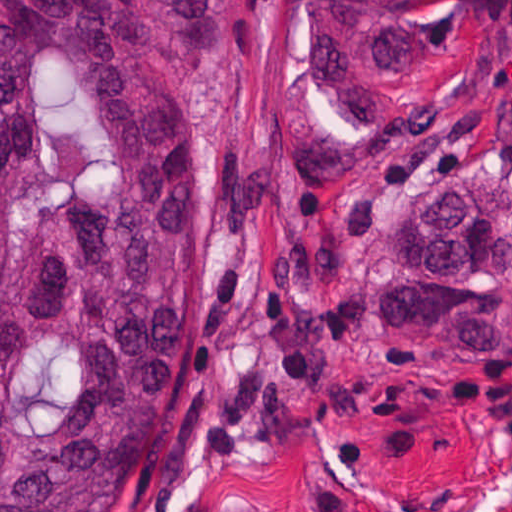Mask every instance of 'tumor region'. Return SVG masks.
<instances>
[{"label": "tumor region", "mask_w": 512, "mask_h": 512, "mask_svg": "<svg viewBox=\"0 0 512 512\" xmlns=\"http://www.w3.org/2000/svg\"><path fill=\"white\" fill-rule=\"evenodd\" d=\"M435 0H293L324 107L399 120ZM209 0H0V512H118L179 437L165 380L203 293L183 76ZM502 177L437 170L364 294L428 346H512Z\"/></svg>", "instance_id": "tumor-region-1"}]
</instances>
